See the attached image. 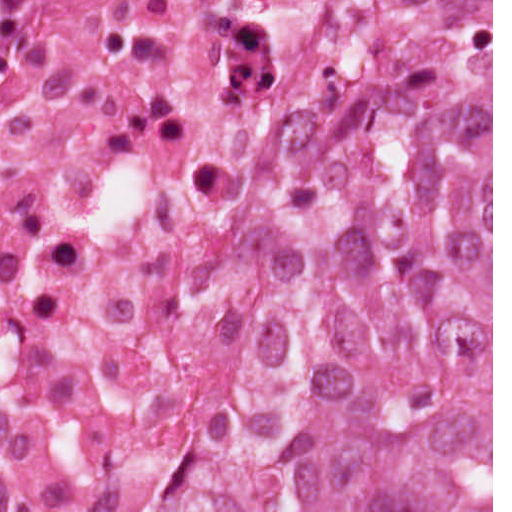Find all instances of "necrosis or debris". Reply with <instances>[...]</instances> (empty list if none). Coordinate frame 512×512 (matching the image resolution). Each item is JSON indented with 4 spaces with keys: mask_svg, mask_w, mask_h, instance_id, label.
<instances>
[{
    "mask_svg": "<svg viewBox=\"0 0 512 512\" xmlns=\"http://www.w3.org/2000/svg\"><path fill=\"white\" fill-rule=\"evenodd\" d=\"M349 1H0V512H170L282 298Z\"/></svg>",
    "mask_w": 512,
    "mask_h": 512,
    "instance_id": "necrosis-or-debris-1",
    "label": "necrosis or debris"
}]
</instances>
